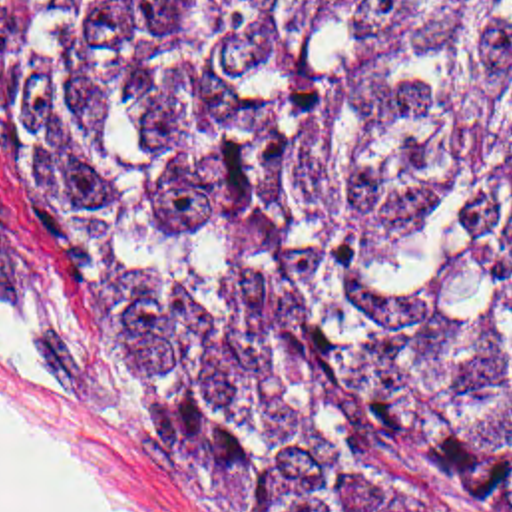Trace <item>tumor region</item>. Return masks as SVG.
I'll return each instance as SVG.
<instances>
[{"label": "tumor region", "mask_w": 512, "mask_h": 512, "mask_svg": "<svg viewBox=\"0 0 512 512\" xmlns=\"http://www.w3.org/2000/svg\"><path fill=\"white\" fill-rule=\"evenodd\" d=\"M0 177L228 512H512V0H7Z\"/></svg>", "instance_id": "1"}]
</instances>
